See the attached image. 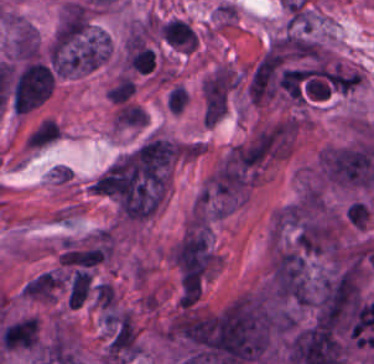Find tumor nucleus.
Returning <instances> with one entry per match:
<instances>
[{
  "label": "tumor nucleus",
  "mask_w": 374,
  "mask_h": 364,
  "mask_svg": "<svg viewBox=\"0 0 374 364\" xmlns=\"http://www.w3.org/2000/svg\"><path fill=\"white\" fill-rule=\"evenodd\" d=\"M110 57V37L92 24L53 37L52 67L60 76L87 74Z\"/></svg>",
  "instance_id": "1"
},
{
  "label": "tumor nucleus",
  "mask_w": 374,
  "mask_h": 364,
  "mask_svg": "<svg viewBox=\"0 0 374 364\" xmlns=\"http://www.w3.org/2000/svg\"><path fill=\"white\" fill-rule=\"evenodd\" d=\"M55 76L39 59L24 64L14 75L11 106L14 112H29L41 105L53 92Z\"/></svg>",
  "instance_id": "2"
},
{
  "label": "tumor nucleus",
  "mask_w": 374,
  "mask_h": 364,
  "mask_svg": "<svg viewBox=\"0 0 374 364\" xmlns=\"http://www.w3.org/2000/svg\"><path fill=\"white\" fill-rule=\"evenodd\" d=\"M91 25L89 8L82 3L69 1L62 9L54 29V39L63 43L81 40Z\"/></svg>",
  "instance_id": "3"
},
{
  "label": "tumor nucleus",
  "mask_w": 374,
  "mask_h": 364,
  "mask_svg": "<svg viewBox=\"0 0 374 364\" xmlns=\"http://www.w3.org/2000/svg\"><path fill=\"white\" fill-rule=\"evenodd\" d=\"M39 38L34 27L24 21L14 23L11 40V57L18 62L38 59Z\"/></svg>",
  "instance_id": "4"
},
{
  "label": "tumor nucleus",
  "mask_w": 374,
  "mask_h": 364,
  "mask_svg": "<svg viewBox=\"0 0 374 364\" xmlns=\"http://www.w3.org/2000/svg\"><path fill=\"white\" fill-rule=\"evenodd\" d=\"M91 284V272L74 270L70 275L66 304L71 309H79L88 296Z\"/></svg>",
  "instance_id": "5"
}]
</instances>
